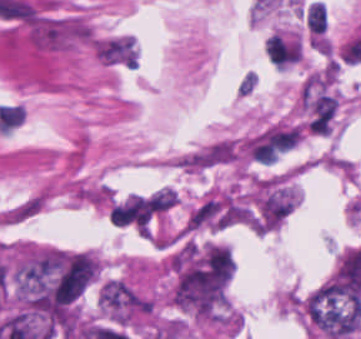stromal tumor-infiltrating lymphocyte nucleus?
I'll list each match as a JSON object with an SVG mask.
<instances>
[{
  "instance_id": "obj_1",
  "label": "stromal tumor-infiltrating lymphocyte nucleus",
  "mask_w": 361,
  "mask_h": 339,
  "mask_svg": "<svg viewBox=\"0 0 361 339\" xmlns=\"http://www.w3.org/2000/svg\"><path fill=\"white\" fill-rule=\"evenodd\" d=\"M307 23L312 33H323L327 26V9L324 2L312 1L307 8Z\"/></svg>"
},
{
  "instance_id": "obj_2",
  "label": "stromal tumor-infiltrating lymphocyte nucleus",
  "mask_w": 361,
  "mask_h": 339,
  "mask_svg": "<svg viewBox=\"0 0 361 339\" xmlns=\"http://www.w3.org/2000/svg\"><path fill=\"white\" fill-rule=\"evenodd\" d=\"M178 199L173 189L162 188L152 194L148 203L152 210H165L170 208Z\"/></svg>"
},
{
  "instance_id": "obj_3",
  "label": "stromal tumor-infiltrating lymphocyte nucleus",
  "mask_w": 361,
  "mask_h": 339,
  "mask_svg": "<svg viewBox=\"0 0 361 339\" xmlns=\"http://www.w3.org/2000/svg\"><path fill=\"white\" fill-rule=\"evenodd\" d=\"M258 84H259L258 71H256L255 69H248L243 72L238 82L236 90L239 95L249 97L254 94Z\"/></svg>"
}]
</instances>
